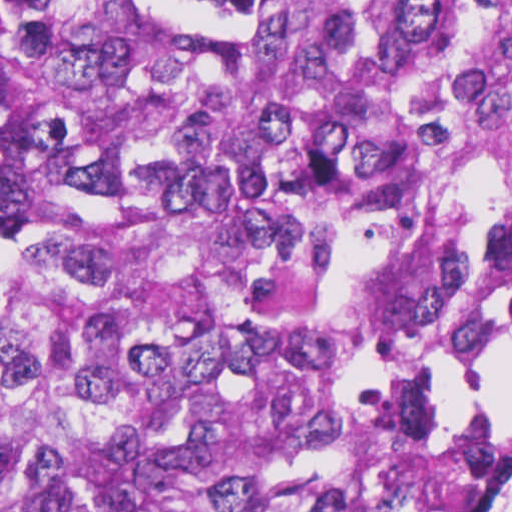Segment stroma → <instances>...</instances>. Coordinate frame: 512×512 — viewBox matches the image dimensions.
I'll return each instance as SVG.
<instances>
[{"instance_id": "stroma-1", "label": "stroma", "mask_w": 512, "mask_h": 512, "mask_svg": "<svg viewBox=\"0 0 512 512\" xmlns=\"http://www.w3.org/2000/svg\"><path fill=\"white\" fill-rule=\"evenodd\" d=\"M0 226L12 241V215L0 212ZM512 302V287L464 347L455 368V393L461 413L479 420L497 412L512 402V384L509 388L483 398L475 380L484 357L491 332ZM502 485L485 501L481 512H497Z\"/></svg>"}]
</instances>
